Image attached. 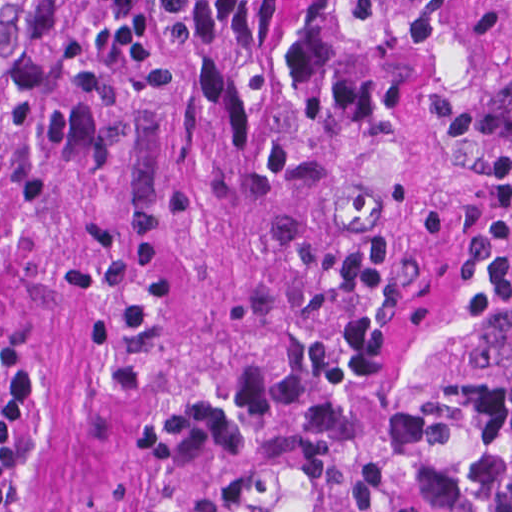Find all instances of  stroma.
<instances>
[{
    "label": "stroma",
    "mask_w": 512,
    "mask_h": 512,
    "mask_svg": "<svg viewBox=\"0 0 512 512\" xmlns=\"http://www.w3.org/2000/svg\"><path fill=\"white\" fill-rule=\"evenodd\" d=\"M399 106L394 75L365 116ZM512 388V0H423L399 106L384 512H450Z\"/></svg>",
    "instance_id": "35a3bbf8"
}]
</instances>
